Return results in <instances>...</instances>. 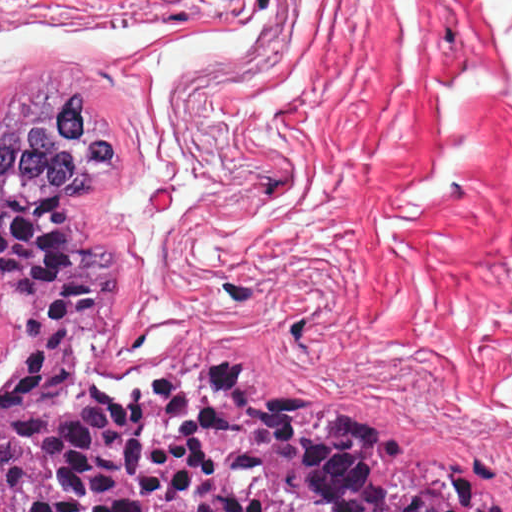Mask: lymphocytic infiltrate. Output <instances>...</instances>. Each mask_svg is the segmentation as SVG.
Listing matches in <instances>:
<instances>
[{
	"mask_svg": "<svg viewBox=\"0 0 512 512\" xmlns=\"http://www.w3.org/2000/svg\"><path fill=\"white\" fill-rule=\"evenodd\" d=\"M218 360H234V361H243V362H251L244 356L240 355H230L218 358ZM284 380L300 383L298 380L292 377H279ZM162 378L158 379L154 383L149 386L150 388H155L156 385ZM302 384V383H300ZM303 385V384H302ZM338 401L346 403L352 407V409L356 412V414L360 417V419L364 422V424L368 427V429L378 436H382L383 438L395 443L396 445L413 452L415 448V438L412 435L411 431L406 429L405 427L398 424L393 419L374 411H369L359 405H356L344 398H335ZM482 455L488 457L489 464L501 475L504 470L505 460L502 454L492 451V450H482L474 453L471 456L475 457H483Z\"/></svg>",
	"mask_w": 512,
	"mask_h": 512,
	"instance_id": "obj_1",
	"label": "lymphocytic infiltrate"
}]
</instances>
